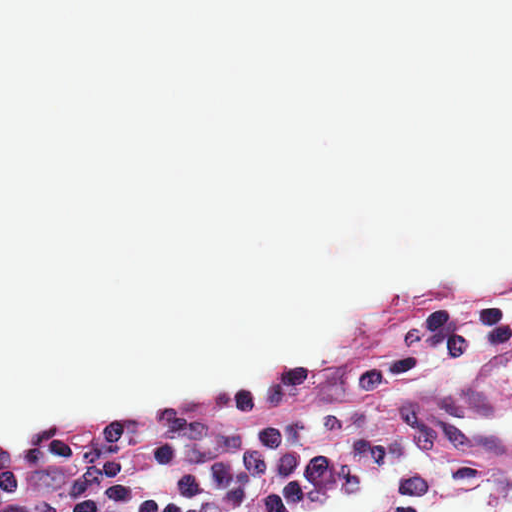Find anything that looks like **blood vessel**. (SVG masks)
Wrapping results in <instances>:
<instances>
[{
	"label": "blood vessel",
	"mask_w": 512,
	"mask_h": 512,
	"mask_svg": "<svg viewBox=\"0 0 512 512\" xmlns=\"http://www.w3.org/2000/svg\"><path fill=\"white\" fill-rule=\"evenodd\" d=\"M402 423L439 450L512 459V399L399 405Z\"/></svg>",
	"instance_id": "8fb6f2fc"
}]
</instances>
